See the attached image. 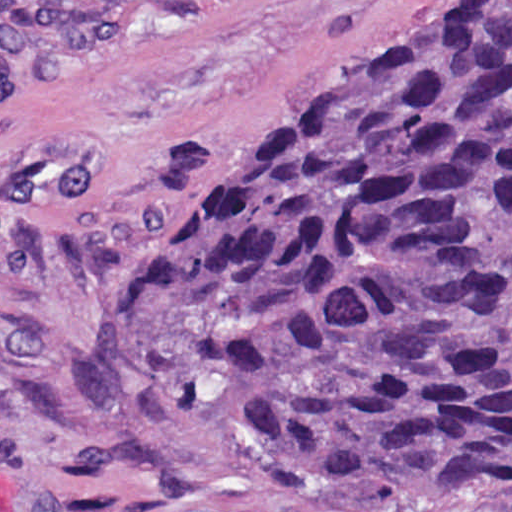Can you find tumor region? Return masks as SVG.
I'll list each match as a JSON object with an SVG mask.
<instances>
[{"instance_id":"tumor-region-1","label":"tumor region","mask_w":512,"mask_h":512,"mask_svg":"<svg viewBox=\"0 0 512 512\" xmlns=\"http://www.w3.org/2000/svg\"><path fill=\"white\" fill-rule=\"evenodd\" d=\"M127 1H0V79ZM196 192L106 325L117 382L246 385L312 488L512 492V0H438Z\"/></svg>"}]
</instances>
